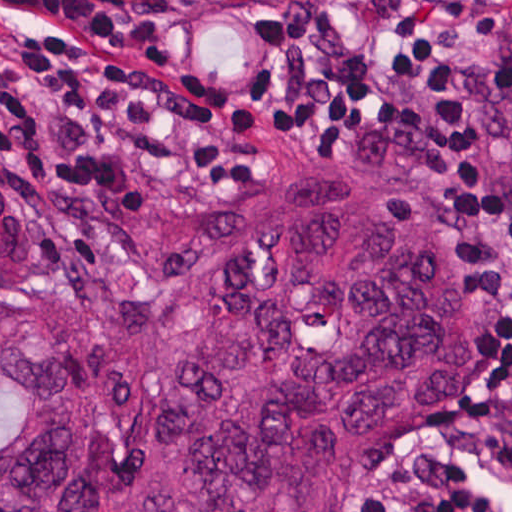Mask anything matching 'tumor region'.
I'll list each match as a JSON object with an SVG mask.
<instances>
[{
  "mask_svg": "<svg viewBox=\"0 0 512 512\" xmlns=\"http://www.w3.org/2000/svg\"><path fill=\"white\" fill-rule=\"evenodd\" d=\"M489 96L512 162V9ZM112 230L155 293L54 283L33 199L0 176V512H341L475 390L469 241L395 191L313 174Z\"/></svg>",
  "mask_w": 512,
  "mask_h": 512,
  "instance_id": "e687c5a6",
  "label": "tumor region"
}]
</instances>
